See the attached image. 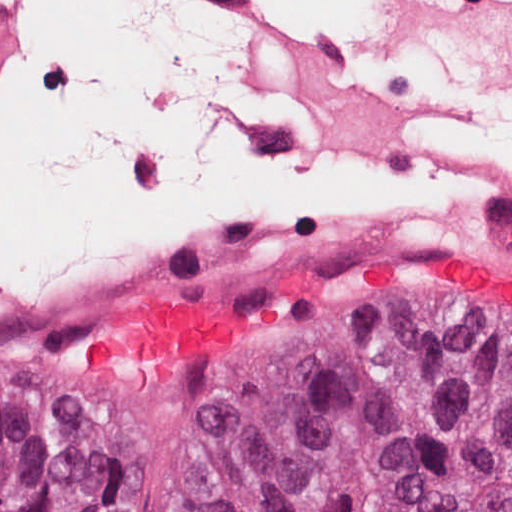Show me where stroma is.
Wrapping results in <instances>:
<instances>
[{
	"label": "stroma",
	"mask_w": 512,
	"mask_h": 512,
	"mask_svg": "<svg viewBox=\"0 0 512 512\" xmlns=\"http://www.w3.org/2000/svg\"><path fill=\"white\" fill-rule=\"evenodd\" d=\"M420 251L430 250L238 260L0 322V378L50 388L87 416L111 459L110 512H200L257 380L290 333L310 320L387 322L375 316L405 312L512 344V317ZM443 251L512 274V250ZM156 298H191L228 315L238 330L161 373L77 368L78 347L103 317Z\"/></svg>",
	"instance_id": "obj_1"
}]
</instances>
